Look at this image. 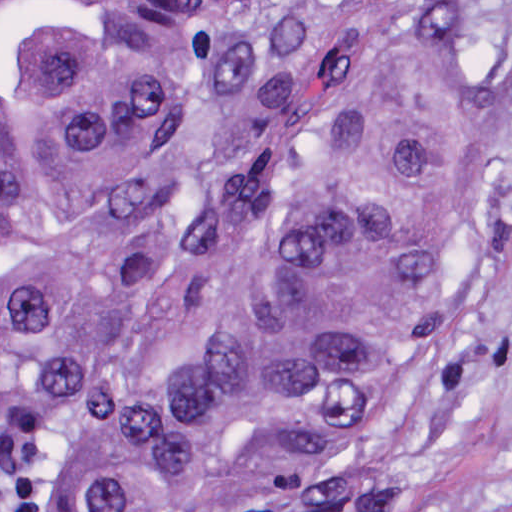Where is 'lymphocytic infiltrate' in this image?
<instances>
[{"label": "lymphocytic infiltrate", "instance_id": "lymphocytic-infiltrate-1", "mask_svg": "<svg viewBox=\"0 0 512 512\" xmlns=\"http://www.w3.org/2000/svg\"><path fill=\"white\" fill-rule=\"evenodd\" d=\"M0 512H155L55 466L47 448L0 429Z\"/></svg>", "mask_w": 512, "mask_h": 512}]
</instances>
